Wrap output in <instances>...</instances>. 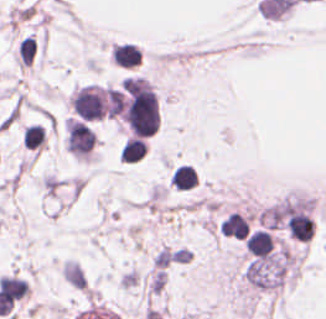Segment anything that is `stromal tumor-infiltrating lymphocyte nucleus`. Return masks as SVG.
Instances as JSON below:
<instances>
[{"instance_id":"abfb95fc","label":"stromal tumor-infiltrating lymphocyte nucleus","mask_w":326,"mask_h":319,"mask_svg":"<svg viewBox=\"0 0 326 319\" xmlns=\"http://www.w3.org/2000/svg\"><path fill=\"white\" fill-rule=\"evenodd\" d=\"M43 140L44 131L42 126H40L38 123L25 125L21 137L22 145L33 149L39 145H42Z\"/></svg>"},{"instance_id":"52c7bb5b","label":"stromal tumor-infiltrating lymphocyte nucleus","mask_w":326,"mask_h":319,"mask_svg":"<svg viewBox=\"0 0 326 319\" xmlns=\"http://www.w3.org/2000/svg\"><path fill=\"white\" fill-rule=\"evenodd\" d=\"M169 181L176 190H190L197 185L196 174L191 166H177L170 174Z\"/></svg>"},{"instance_id":"3290ff9b","label":"stromal tumor-infiltrating lymphocyte nucleus","mask_w":326,"mask_h":319,"mask_svg":"<svg viewBox=\"0 0 326 319\" xmlns=\"http://www.w3.org/2000/svg\"><path fill=\"white\" fill-rule=\"evenodd\" d=\"M146 150L141 138L129 137L120 149V157L123 161L135 162L142 158Z\"/></svg>"},{"instance_id":"bc302bb0","label":"stromal tumor-infiltrating lymphocyte nucleus","mask_w":326,"mask_h":319,"mask_svg":"<svg viewBox=\"0 0 326 319\" xmlns=\"http://www.w3.org/2000/svg\"><path fill=\"white\" fill-rule=\"evenodd\" d=\"M110 58L115 64L122 67H132L140 61L139 47L129 43H121L114 45Z\"/></svg>"}]
</instances>
